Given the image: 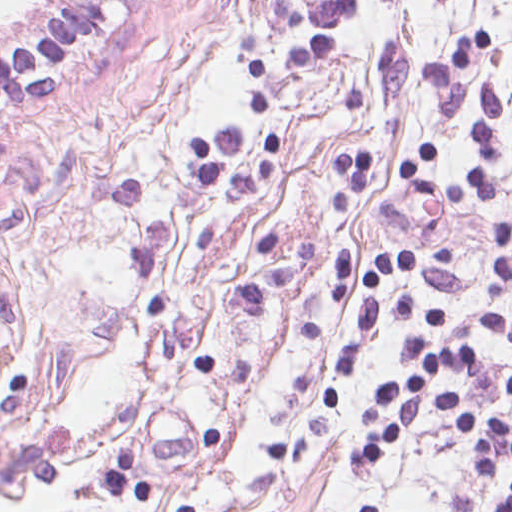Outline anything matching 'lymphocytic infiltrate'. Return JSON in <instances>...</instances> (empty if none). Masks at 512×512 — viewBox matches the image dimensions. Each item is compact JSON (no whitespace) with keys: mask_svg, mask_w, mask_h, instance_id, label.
I'll use <instances>...</instances> for the list:
<instances>
[{"mask_svg":"<svg viewBox=\"0 0 512 512\" xmlns=\"http://www.w3.org/2000/svg\"><path fill=\"white\" fill-rule=\"evenodd\" d=\"M118 0H68L58 18L46 29L20 45L0 50V105L28 100L58 83H45L36 73L45 66L75 53L96 40L113 22ZM357 7V0H291L270 4L279 28L293 36L302 26L308 43L287 52V66L302 70L324 60L333 51V29L339 18ZM297 74V75H298ZM497 92L488 85L480 90L476 121V160L451 175L425 173L436 143H425L395 165V178L417 194L435 200H461L471 188L492 200L497 189L493 174L499 157V136L491 122ZM339 167L346 181L335 189L334 207L345 213L354 192L365 183L367 153L339 151ZM452 246L406 244L375 256L365 276L371 295L363 302L352 332L338 348V374L349 375L361 353L373 339L380 320L394 315L409 318L400 342V355L412 373L407 380H386L379 385L365 408L360 423L374 435L358 442L348 452L347 464L357 470L385 461L399 451L406 439L432 415L460 446L472 475L481 486H492L495 470L512 465V422L495 410L471 407L470 398L457 381L434 389L429 380L447 371L482 373L488 361L475 341L460 339L426 344L448 322L443 311L423 307L414 299L380 294L384 275L450 267ZM478 327L512 343V318L476 312ZM487 335V334H486ZM107 488L119 501L133 497L142 501L152 487L140 481L136 461L128 451L117 453L105 466ZM359 512H373V505ZM397 512V511H396ZM498 512H512V486Z\"/></svg>","mask_w":512,"mask_h":512,"instance_id":"obj_1","label":"lymphocytic infiltrate"}]
</instances>
